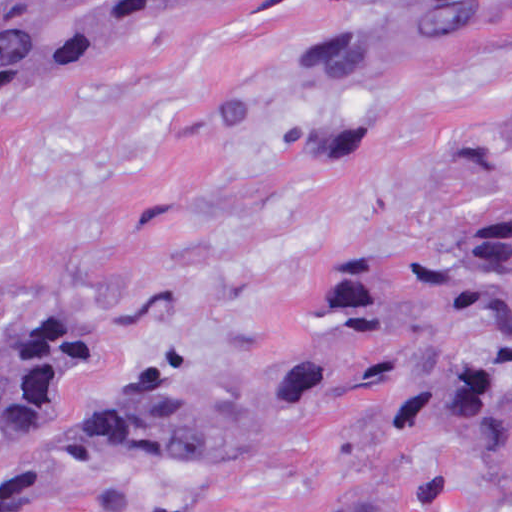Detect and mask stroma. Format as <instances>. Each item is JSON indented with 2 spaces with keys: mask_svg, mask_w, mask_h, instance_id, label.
Returning a JSON list of instances; mask_svg holds the SVG:
<instances>
[{
  "mask_svg": "<svg viewBox=\"0 0 512 512\" xmlns=\"http://www.w3.org/2000/svg\"><path fill=\"white\" fill-rule=\"evenodd\" d=\"M386 0H227L117 39L0 116V340L45 313L105 348L0 461V512H508L445 432L381 391L267 377L316 346L347 260L444 252L512 193V17L365 89L376 143L304 145L343 97L290 87ZM203 393L111 424L131 381Z\"/></svg>",
  "mask_w": 512,
  "mask_h": 512,
  "instance_id": "obj_1",
  "label": "stroma"
}]
</instances>
